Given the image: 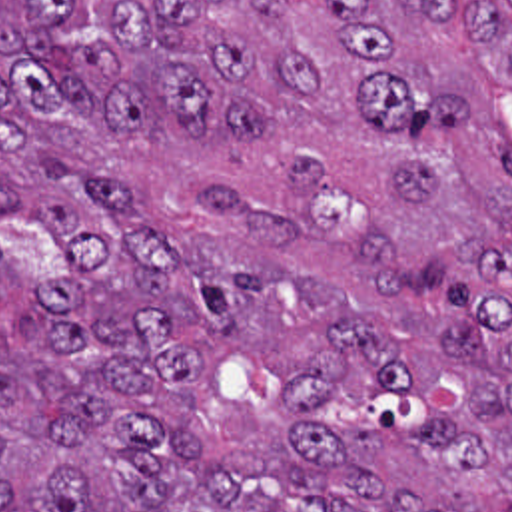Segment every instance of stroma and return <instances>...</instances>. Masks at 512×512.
I'll list each match as a JSON object with an SVG mask.
<instances>
[{
	"instance_id": "stroma-1",
	"label": "stroma",
	"mask_w": 512,
	"mask_h": 512,
	"mask_svg": "<svg viewBox=\"0 0 512 512\" xmlns=\"http://www.w3.org/2000/svg\"><path fill=\"white\" fill-rule=\"evenodd\" d=\"M117 2L119 0H95V6L101 12H107V10H115ZM476 2L490 6L496 12H500L504 18L512 20V0H476ZM508 108H512V86L498 84L494 90V98H492V118H500Z\"/></svg>"
}]
</instances>
